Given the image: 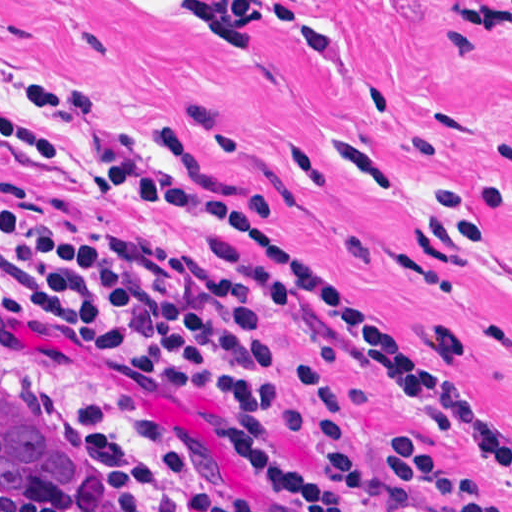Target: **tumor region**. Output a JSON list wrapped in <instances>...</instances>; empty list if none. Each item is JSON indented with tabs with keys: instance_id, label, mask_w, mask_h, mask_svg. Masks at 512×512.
I'll use <instances>...</instances> for the list:
<instances>
[{
	"instance_id": "e687c5a6",
	"label": "tumor region",
	"mask_w": 512,
	"mask_h": 512,
	"mask_svg": "<svg viewBox=\"0 0 512 512\" xmlns=\"http://www.w3.org/2000/svg\"><path fill=\"white\" fill-rule=\"evenodd\" d=\"M130 468L81 442L44 388L0 353V492L29 504L126 499Z\"/></svg>"
}]
</instances>
